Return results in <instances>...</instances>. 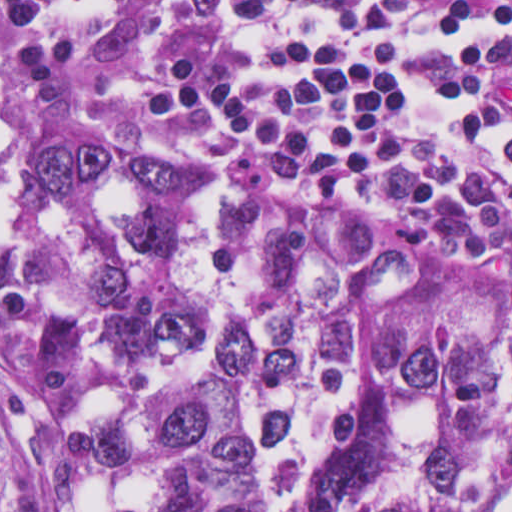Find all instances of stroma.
I'll use <instances>...</instances> for the list:
<instances>
[{
  "label": "stroma",
  "instance_id": "35a3bbf8",
  "mask_svg": "<svg viewBox=\"0 0 512 512\" xmlns=\"http://www.w3.org/2000/svg\"><path fill=\"white\" fill-rule=\"evenodd\" d=\"M107 102L91 98L64 78L44 71L17 54L4 29L0 0V512H1V139L24 145L57 137H85L111 144L169 173L212 185L233 197L291 198L368 220L329 200L269 192L245 186L194 157L163 144L116 130L100 117ZM392 228L417 246L430 268L442 275L512 280V257Z\"/></svg>",
  "mask_w": 512,
  "mask_h": 512
}]
</instances>
